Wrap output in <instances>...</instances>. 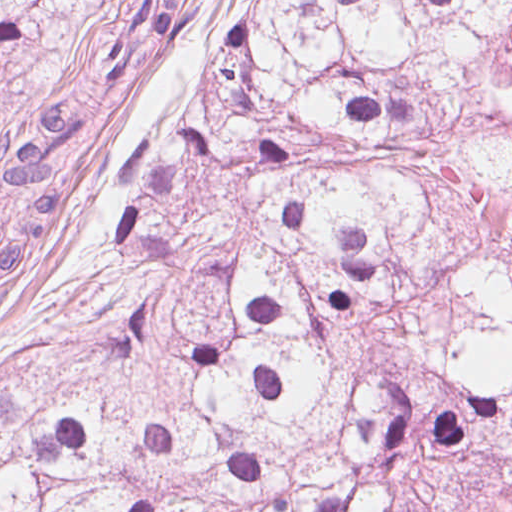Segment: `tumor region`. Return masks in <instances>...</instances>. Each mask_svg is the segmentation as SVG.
Wrapping results in <instances>:
<instances>
[{
	"mask_svg": "<svg viewBox=\"0 0 512 512\" xmlns=\"http://www.w3.org/2000/svg\"><path fill=\"white\" fill-rule=\"evenodd\" d=\"M230 2L99 284L0 352V512H512V0ZM195 5L1 127L0 287Z\"/></svg>",
	"mask_w": 512,
	"mask_h": 512,
	"instance_id": "tumor-region-1",
	"label": "tumor region"
}]
</instances>
